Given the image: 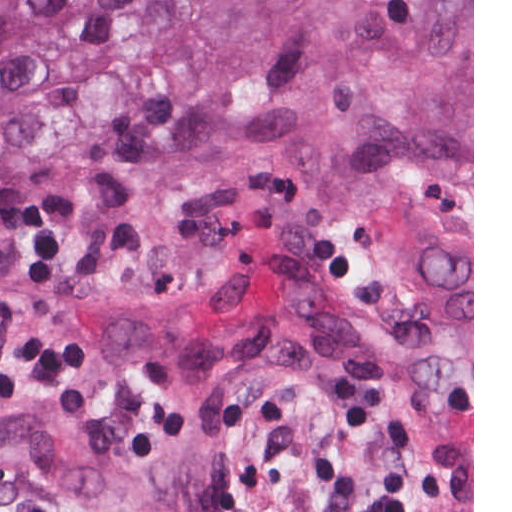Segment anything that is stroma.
Returning <instances> with one entry per match:
<instances>
[{"label": "stroma", "instance_id": "35a3bbf8", "mask_svg": "<svg viewBox=\"0 0 512 512\" xmlns=\"http://www.w3.org/2000/svg\"><path fill=\"white\" fill-rule=\"evenodd\" d=\"M391 464L362 390L338 368L267 361L230 393L227 480L239 512H369ZM0 512H107L54 474L0 470ZM474 512V0H473Z\"/></svg>", "mask_w": 512, "mask_h": 512}]
</instances>
